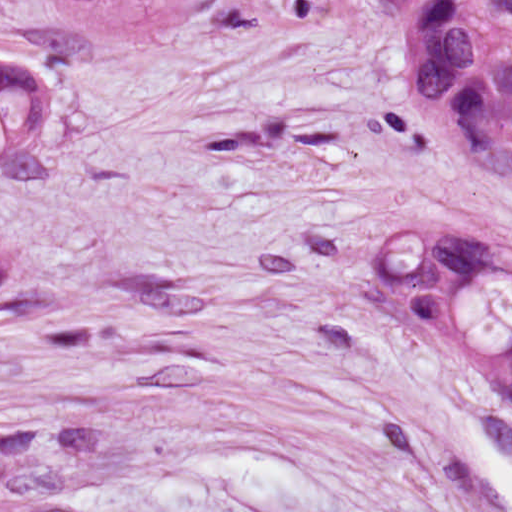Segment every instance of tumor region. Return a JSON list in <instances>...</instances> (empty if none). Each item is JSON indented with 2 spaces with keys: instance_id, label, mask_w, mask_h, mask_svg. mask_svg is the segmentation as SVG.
I'll use <instances>...</instances> for the list:
<instances>
[{
  "instance_id": "tumor-region-1",
  "label": "tumor region",
  "mask_w": 512,
  "mask_h": 512,
  "mask_svg": "<svg viewBox=\"0 0 512 512\" xmlns=\"http://www.w3.org/2000/svg\"><path fill=\"white\" fill-rule=\"evenodd\" d=\"M454 148L512 170V60L414 104ZM366 282L422 347L500 383L512 403V250L476 230L397 228Z\"/></svg>"
}]
</instances>
